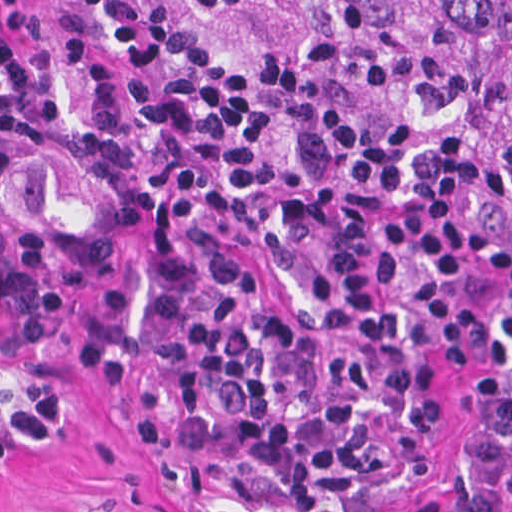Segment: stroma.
Listing matches in <instances>:
<instances>
[{"instance_id": "obj_1", "label": "stroma", "mask_w": 512, "mask_h": 512, "mask_svg": "<svg viewBox=\"0 0 512 512\" xmlns=\"http://www.w3.org/2000/svg\"><path fill=\"white\" fill-rule=\"evenodd\" d=\"M279 100L315 101L376 135L419 128L466 142L512 175V143L471 120L444 71L423 68L342 19L249 0H175ZM145 255L67 269L0 292V512H204L174 491L124 416ZM493 356L448 363L442 453L389 512H512V219L476 297Z\"/></svg>"}]
</instances>
